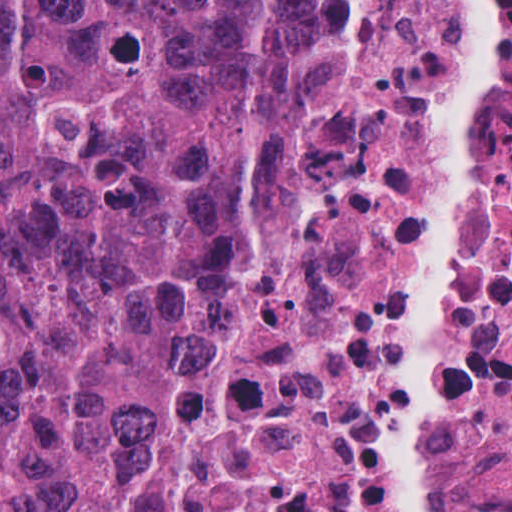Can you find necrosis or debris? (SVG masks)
I'll use <instances>...</instances> for the list:
<instances>
[{
	"label": "necrosis or debris",
	"mask_w": 512,
	"mask_h": 512,
	"mask_svg": "<svg viewBox=\"0 0 512 512\" xmlns=\"http://www.w3.org/2000/svg\"><path fill=\"white\" fill-rule=\"evenodd\" d=\"M478 0H313L289 169L210 281L178 512H512V0L488 109L447 95Z\"/></svg>",
	"instance_id": "1"
}]
</instances>
